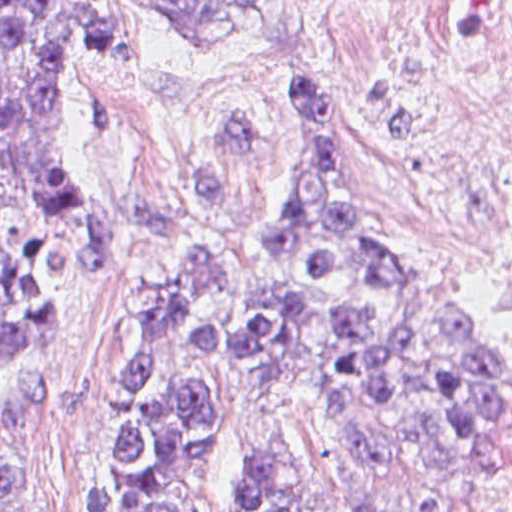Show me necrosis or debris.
I'll list each match as a JSON object with an SVG mask.
<instances>
[{"label":"necrosis or debris","mask_w":512,"mask_h":512,"mask_svg":"<svg viewBox=\"0 0 512 512\" xmlns=\"http://www.w3.org/2000/svg\"><path fill=\"white\" fill-rule=\"evenodd\" d=\"M362 128L385 204L471 262L512 325V0H380Z\"/></svg>","instance_id":"1"}]
</instances>
